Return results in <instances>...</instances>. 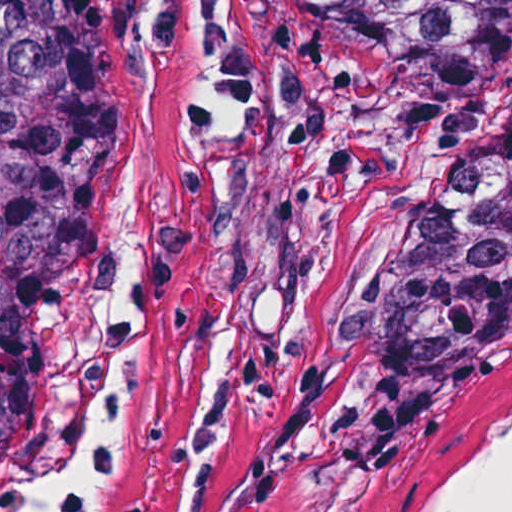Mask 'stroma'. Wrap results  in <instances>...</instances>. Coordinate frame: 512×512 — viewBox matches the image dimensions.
I'll return each mask as SVG.
<instances>
[{
    "label": "stroma",
    "mask_w": 512,
    "mask_h": 512,
    "mask_svg": "<svg viewBox=\"0 0 512 512\" xmlns=\"http://www.w3.org/2000/svg\"><path fill=\"white\" fill-rule=\"evenodd\" d=\"M152 0H79L65 77V272L0 512L96 339V209L121 67ZM512 113L411 82L361 32L273 0H174L143 459L96 512H427L512 431V319L389 481L370 358L426 211Z\"/></svg>",
    "instance_id": "stroma-1"
}]
</instances>
